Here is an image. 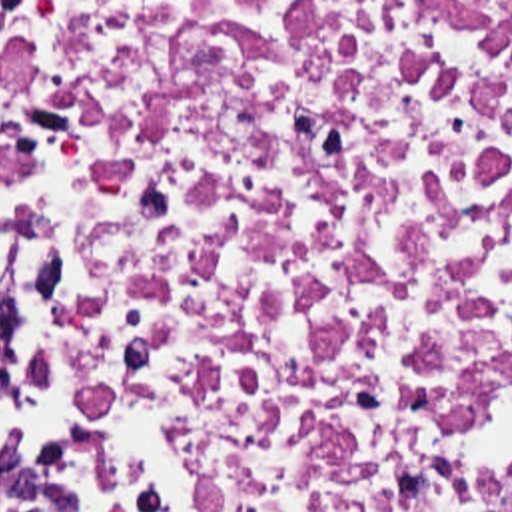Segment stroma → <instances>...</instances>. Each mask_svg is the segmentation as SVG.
Wrapping results in <instances>:
<instances>
[{
	"label": "stroma",
	"instance_id": "obj_1",
	"mask_svg": "<svg viewBox=\"0 0 512 512\" xmlns=\"http://www.w3.org/2000/svg\"><path fill=\"white\" fill-rule=\"evenodd\" d=\"M0 2H512V0H0ZM0 293L9 305V351L25 347L21 339V266L0 232Z\"/></svg>",
	"mask_w": 512,
	"mask_h": 512
}]
</instances>
